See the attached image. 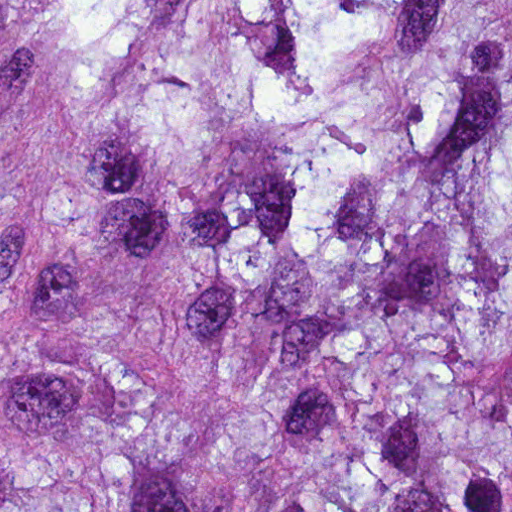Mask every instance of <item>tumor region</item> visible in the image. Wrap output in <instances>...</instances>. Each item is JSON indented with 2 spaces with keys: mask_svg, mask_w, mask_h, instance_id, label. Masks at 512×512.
<instances>
[{
  "mask_svg": "<svg viewBox=\"0 0 512 512\" xmlns=\"http://www.w3.org/2000/svg\"><path fill=\"white\" fill-rule=\"evenodd\" d=\"M0 512H512V0H0Z\"/></svg>",
  "mask_w": 512,
  "mask_h": 512,
  "instance_id": "tumor-region-1",
  "label": "tumor region"
}]
</instances>
